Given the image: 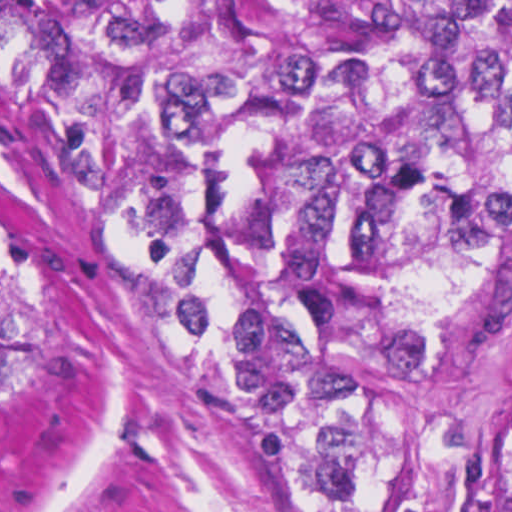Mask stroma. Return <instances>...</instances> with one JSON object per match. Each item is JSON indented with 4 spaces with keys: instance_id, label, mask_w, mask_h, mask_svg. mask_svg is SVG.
Instances as JSON below:
<instances>
[{
    "instance_id": "35a3bbf8",
    "label": "stroma",
    "mask_w": 512,
    "mask_h": 512,
    "mask_svg": "<svg viewBox=\"0 0 512 512\" xmlns=\"http://www.w3.org/2000/svg\"><path fill=\"white\" fill-rule=\"evenodd\" d=\"M0 73L54 137L182 360L0 124V250L26 368L0 512H512V316L384 392L352 463L219 293L136 112L50 0H0Z\"/></svg>"
}]
</instances>
